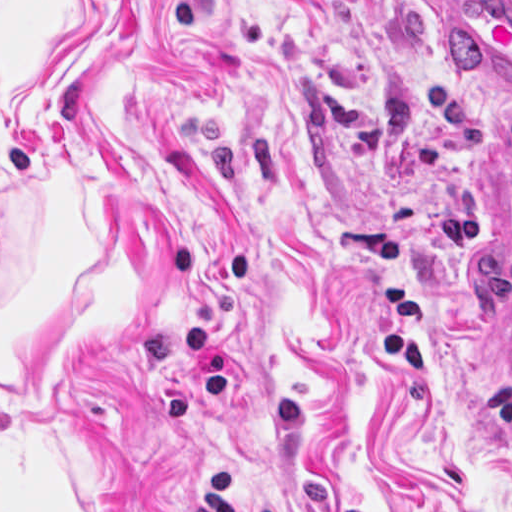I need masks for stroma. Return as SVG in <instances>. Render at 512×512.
<instances>
[{
	"mask_svg": "<svg viewBox=\"0 0 512 512\" xmlns=\"http://www.w3.org/2000/svg\"><path fill=\"white\" fill-rule=\"evenodd\" d=\"M504 132L512 0H0V512L512 505Z\"/></svg>",
	"mask_w": 512,
	"mask_h": 512,
	"instance_id": "1",
	"label": "stroma"
}]
</instances>
